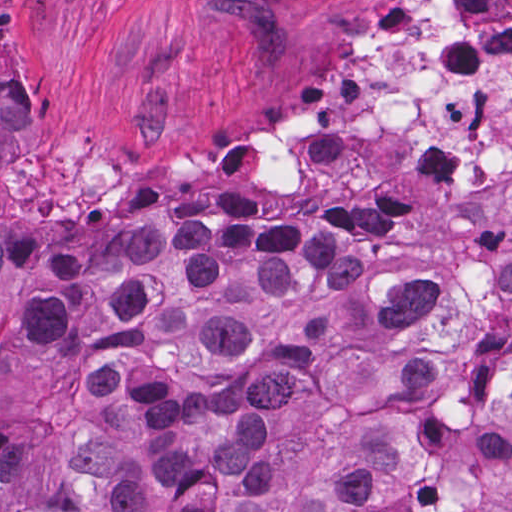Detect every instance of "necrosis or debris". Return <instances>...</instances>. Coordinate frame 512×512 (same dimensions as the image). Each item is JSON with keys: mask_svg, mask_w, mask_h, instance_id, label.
I'll return each mask as SVG.
<instances>
[{"mask_svg": "<svg viewBox=\"0 0 512 512\" xmlns=\"http://www.w3.org/2000/svg\"><path fill=\"white\" fill-rule=\"evenodd\" d=\"M512 175V0H391L333 90L265 131L226 129L218 163L135 175L32 170L19 199L243 193L381 199L404 215Z\"/></svg>", "mask_w": 512, "mask_h": 512, "instance_id": "necrosis-or-debris-1", "label": "necrosis or debris"}]
</instances>
